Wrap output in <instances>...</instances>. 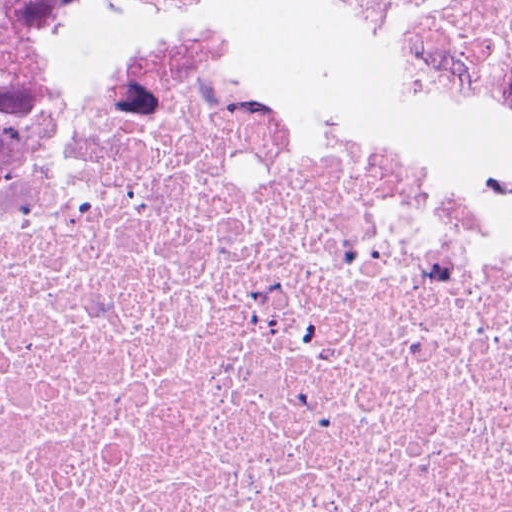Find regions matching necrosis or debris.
Returning <instances> with one entry per match:
<instances>
[{
    "instance_id": "4bbe7bcc",
    "label": "necrosis or debris",
    "mask_w": 512,
    "mask_h": 512,
    "mask_svg": "<svg viewBox=\"0 0 512 512\" xmlns=\"http://www.w3.org/2000/svg\"><path fill=\"white\" fill-rule=\"evenodd\" d=\"M0 512H512V181L209 0H0Z\"/></svg>"
}]
</instances>
